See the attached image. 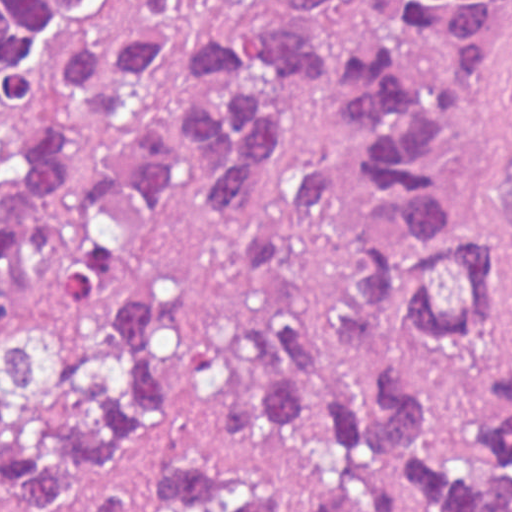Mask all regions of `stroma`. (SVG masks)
Returning <instances> with one entry per match:
<instances>
[{
  "mask_svg": "<svg viewBox=\"0 0 512 512\" xmlns=\"http://www.w3.org/2000/svg\"><path fill=\"white\" fill-rule=\"evenodd\" d=\"M389 1L342 0L311 23V43L327 62V87L307 99L279 96L272 116L284 177L260 217L238 225L178 201L160 204L142 243L121 251L98 284L74 295L51 259L33 255L25 275L0 294L1 351L41 329L83 341L107 337L123 311L163 291L173 307V345L162 378L166 448L113 486L129 490L146 512H167L152 474L168 458L248 455L262 439L250 375L231 336L266 310L238 251L246 233L287 220L294 177L305 162H349L354 141L341 82L354 43ZM441 160L454 200L481 225L496 261L495 298L477 345L429 353L418 367L441 428L459 446L477 442L488 428L491 386L512 356V253L499 217L512 172V7L479 100L445 138ZM105 491L21 512H91ZM0 512H10L1 499Z\"/></svg>",
  "mask_w": 512,
  "mask_h": 512,
  "instance_id": "obj_1",
  "label": "stroma"
}]
</instances>
